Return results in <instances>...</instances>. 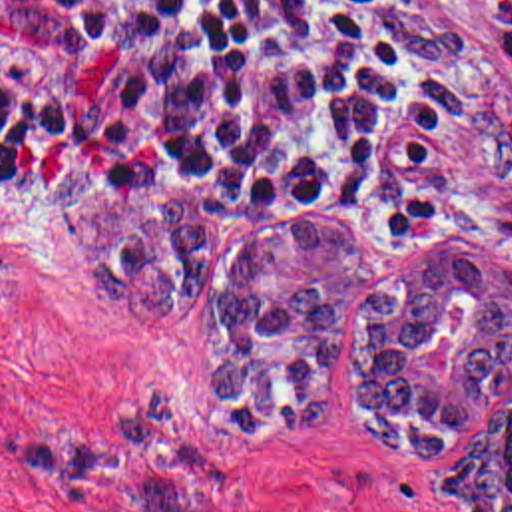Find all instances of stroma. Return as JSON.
<instances>
[{"label":"stroma","mask_w":512,"mask_h":512,"mask_svg":"<svg viewBox=\"0 0 512 512\" xmlns=\"http://www.w3.org/2000/svg\"><path fill=\"white\" fill-rule=\"evenodd\" d=\"M392 20L404 59L446 97V125L392 149L390 207L261 211L201 183L105 173L75 141L0 171V512H85L30 476L18 440L99 430L157 388L179 398L199 450L219 464L223 512H456L440 492L446 458H400L350 424L356 308L370 284L462 229L512 249V0H392ZM58 165L83 175L81 201L117 189L197 193L209 209L203 306H143L97 282L44 195ZM297 223L354 231L370 247V273L350 286L330 416L285 438H245L211 410L227 360L221 286L233 257Z\"/></svg>","instance_id":"stroma-1"}]
</instances>
